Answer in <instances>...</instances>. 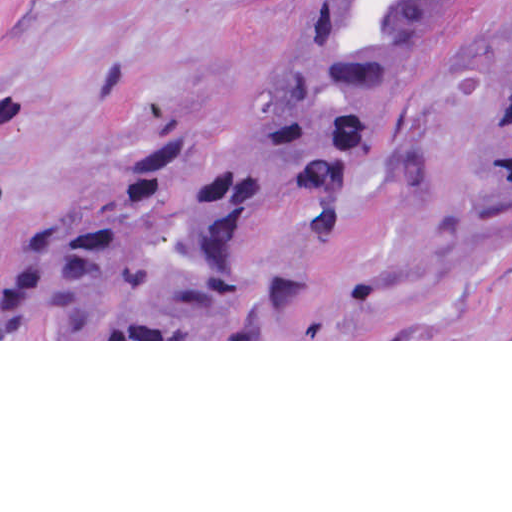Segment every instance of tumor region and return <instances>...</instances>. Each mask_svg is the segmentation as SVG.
Here are the masks:
<instances>
[{
    "label": "tumor region",
    "instance_id": "obj_1",
    "mask_svg": "<svg viewBox=\"0 0 512 512\" xmlns=\"http://www.w3.org/2000/svg\"><path fill=\"white\" fill-rule=\"evenodd\" d=\"M432 0H317L272 58L239 131L198 165L163 128L93 165L18 225L10 282L153 336H231L292 307L277 230L350 200ZM472 200L512 211V71L471 142Z\"/></svg>",
    "mask_w": 512,
    "mask_h": 512
}]
</instances>
